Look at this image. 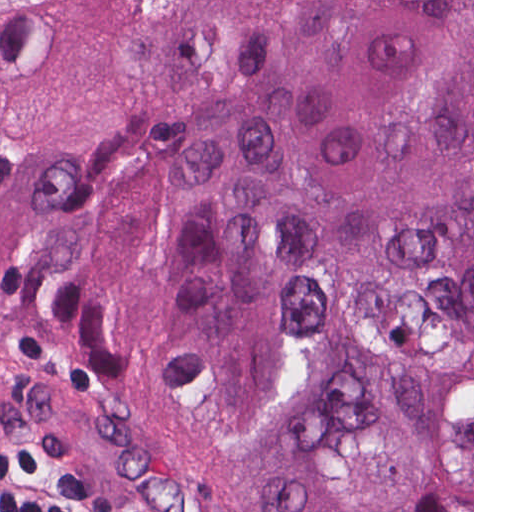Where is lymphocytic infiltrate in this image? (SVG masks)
Wrapping results in <instances>:
<instances>
[{
    "label": "lymphocytic infiltrate",
    "instance_id": "obj_1",
    "mask_svg": "<svg viewBox=\"0 0 512 512\" xmlns=\"http://www.w3.org/2000/svg\"><path fill=\"white\" fill-rule=\"evenodd\" d=\"M0 512H98L33 437L0 429Z\"/></svg>",
    "mask_w": 512,
    "mask_h": 512
}]
</instances>
